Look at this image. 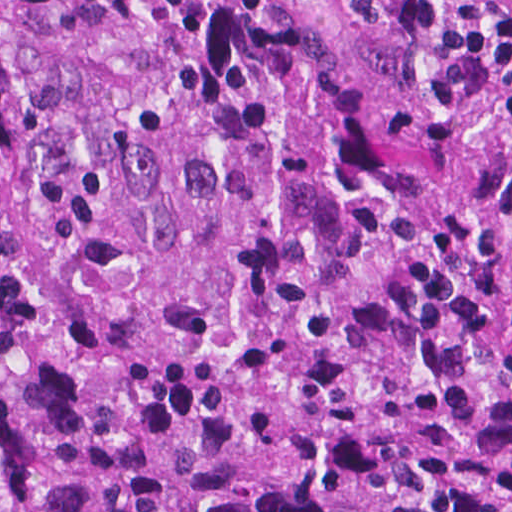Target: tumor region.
I'll return each mask as SVG.
<instances>
[{"mask_svg":"<svg viewBox=\"0 0 512 512\" xmlns=\"http://www.w3.org/2000/svg\"><path fill=\"white\" fill-rule=\"evenodd\" d=\"M0 512H512V233L307 0L0 2Z\"/></svg>","mask_w":512,"mask_h":512,"instance_id":"obj_1","label":"tumor region"}]
</instances>
